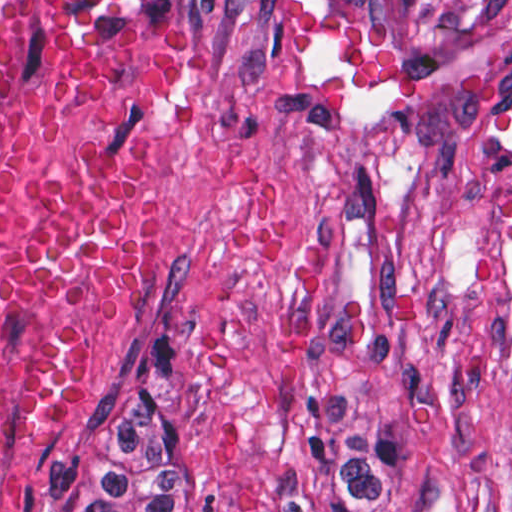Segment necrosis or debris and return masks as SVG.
Wrapping results in <instances>:
<instances>
[{
	"mask_svg": "<svg viewBox=\"0 0 512 512\" xmlns=\"http://www.w3.org/2000/svg\"><path fill=\"white\" fill-rule=\"evenodd\" d=\"M224 76L225 0H0V512H75Z\"/></svg>",
	"mask_w": 512,
	"mask_h": 512,
	"instance_id": "necrosis-or-debris-1",
	"label": "necrosis or debris"
}]
</instances>
